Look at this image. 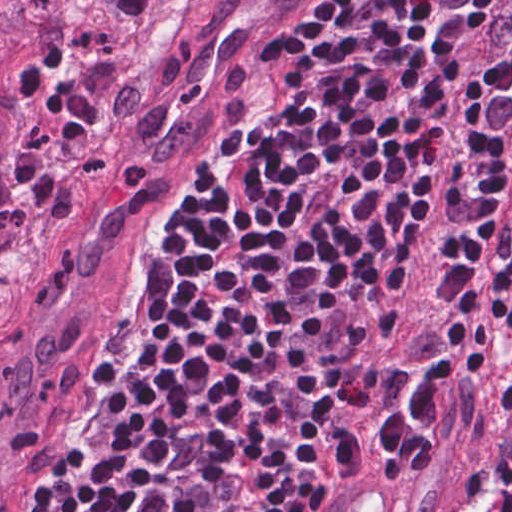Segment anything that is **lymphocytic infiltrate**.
<instances>
[{
    "label": "lymphocytic infiltrate",
    "mask_w": 512,
    "mask_h": 512,
    "mask_svg": "<svg viewBox=\"0 0 512 512\" xmlns=\"http://www.w3.org/2000/svg\"><path fill=\"white\" fill-rule=\"evenodd\" d=\"M55 512H324L369 350L383 464L441 454L512 352V4ZM256 287V288H257ZM512 404V363L506 371ZM456 512H512V445Z\"/></svg>",
    "instance_id": "lymphocytic-infiltrate-1"
}]
</instances>
